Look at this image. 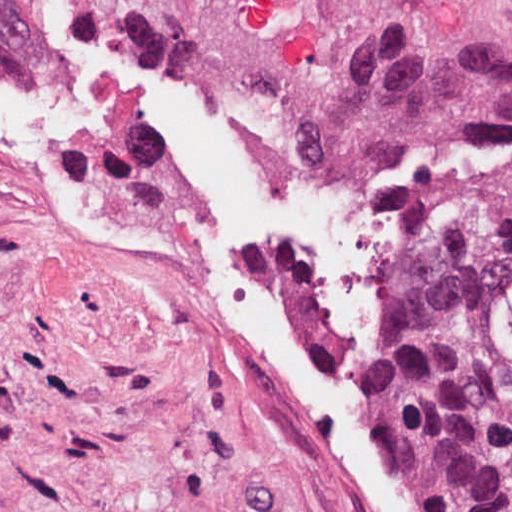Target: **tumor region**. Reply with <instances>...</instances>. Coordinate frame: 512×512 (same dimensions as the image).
Instances as JSON below:
<instances>
[{
    "label": "tumor region",
    "instance_id": "e687c5a6",
    "mask_svg": "<svg viewBox=\"0 0 512 512\" xmlns=\"http://www.w3.org/2000/svg\"><path fill=\"white\" fill-rule=\"evenodd\" d=\"M38 57L0 0V70ZM512 153L387 225L377 254V416L437 512H512Z\"/></svg>",
    "mask_w": 512,
    "mask_h": 512
}]
</instances>
